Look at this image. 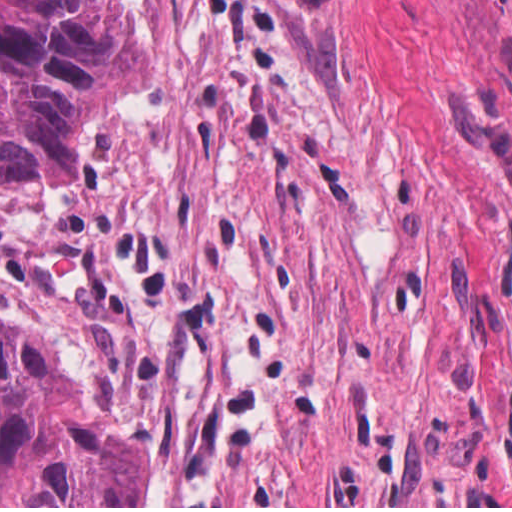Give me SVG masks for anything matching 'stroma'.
Instances as JSON below:
<instances>
[{
	"label": "stroma",
	"mask_w": 512,
	"mask_h": 512,
	"mask_svg": "<svg viewBox=\"0 0 512 512\" xmlns=\"http://www.w3.org/2000/svg\"><path fill=\"white\" fill-rule=\"evenodd\" d=\"M145 62L76 176L0 193V315L512 19V0H98Z\"/></svg>",
	"instance_id": "1"
}]
</instances>
